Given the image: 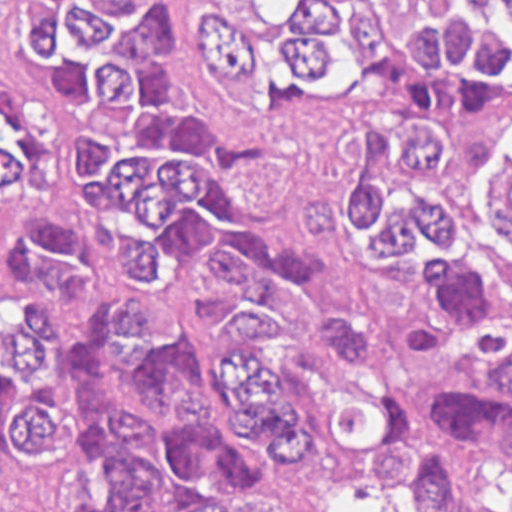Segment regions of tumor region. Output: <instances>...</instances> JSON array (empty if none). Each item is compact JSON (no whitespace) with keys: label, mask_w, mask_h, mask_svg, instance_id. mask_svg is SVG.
<instances>
[{"label":"tumor region","mask_w":512,"mask_h":512,"mask_svg":"<svg viewBox=\"0 0 512 512\" xmlns=\"http://www.w3.org/2000/svg\"><path fill=\"white\" fill-rule=\"evenodd\" d=\"M22 32L47 88L33 113L1 109V512H20L66 429L48 349L83 290L72 228L36 198L42 120L56 93L129 104L81 135L77 165L140 292L97 315L74 369L91 451L53 491L54 512H323L338 497L366 512H455L448 446L512 457V258L474 247L457 211L425 192L443 133L370 126L347 195L311 198L301 237H354L380 265L425 248L431 281L489 333L468 362L394 405L334 399L305 431L272 370L248 348L276 309L331 353L358 356V327L309 293L303 252L259 237L233 200L241 174L272 163L254 138L216 136L163 105L159 49L173 41L162 0H22ZM200 54L230 102L314 110L382 84L436 115L512 108V0H213ZM512 241V161L490 174Z\"/></svg>","instance_id":"e687c5a6"}]
</instances>
